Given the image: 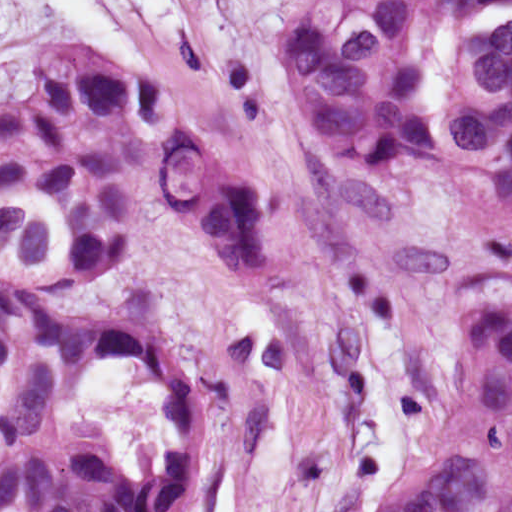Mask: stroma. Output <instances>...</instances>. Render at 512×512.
Segmentation results:
<instances>
[{"label": "stroma", "mask_w": 512, "mask_h": 512, "mask_svg": "<svg viewBox=\"0 0 512 512\" xmlns=\"http://www.w3.org/2000/svg\"><path fill=\"white\" fill-rule=\"evenodd\" d=\"M283 0H170L153 62L197 96L273 233L255 276L159 208L98 270L180 340L200 411V460L168 512H369L423 428L434 355L458 285L512 268V223L432 172L361 170L313 127L280 44ZM9 0L0 92L47 51Z\"/></svg>", "instance_id": "stroma-1"}]
</instances>
